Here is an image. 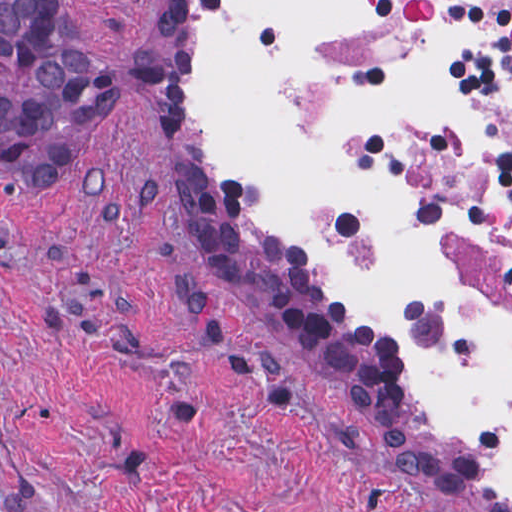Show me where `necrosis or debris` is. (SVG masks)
Wrapping results in <instances>:
<instances>
[{"label":"necrosis or debris","instance_id":"4bbe7bcc","mask_svg":"<svg viewBox=\"0 0 512 512\" xmlns=\"http://www.w3.org/2000/svg\"><path fill=\"white\" fill-rule=\"evenodd\" d=\"M447 21L469 31L459 77L472 129L461 148L431 114H408L407 173L437 234L512 306V0H375L331 26L315 56H387Z\"/></svg>","mask_w":512,"mask_h":512}]
</instances>
